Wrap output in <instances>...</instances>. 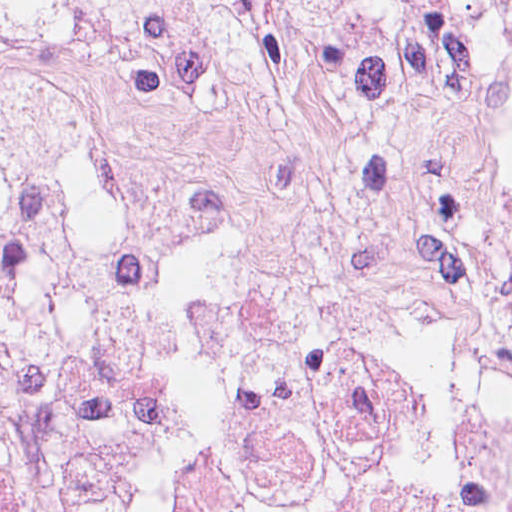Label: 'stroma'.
Listing matches in <instances>:
<instances>
[{"instance_id": "1", "label": "stroma", "mask_w": 512, "mask_h": 512, "mask_svg": "<svg viewBox=\"0 0 512 512\" xmlns=\"http://www.w3.org/2000/svg\"><path fill=\"white\" fill-rule=\"evenodd\" d=\"M0 512H55L2 453Z\"/></svg>"}]
</instances>
